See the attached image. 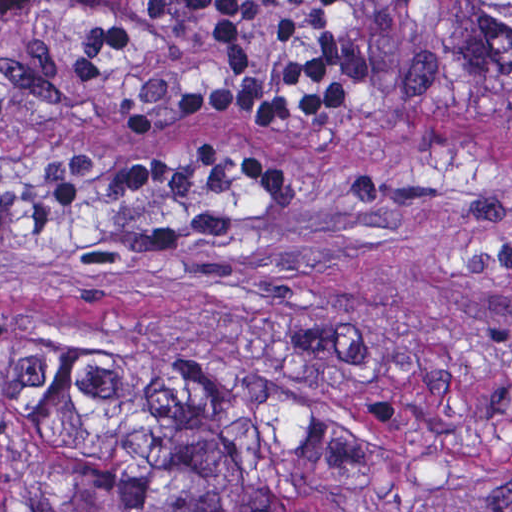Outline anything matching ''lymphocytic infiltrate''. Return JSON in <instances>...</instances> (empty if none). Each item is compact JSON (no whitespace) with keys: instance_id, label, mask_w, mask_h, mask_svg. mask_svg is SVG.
I'll return each instance as SVG.
<instances>
[{"instance_id":"1","label":"lymphocytic infiltrate","mask_w":512,"mask_h":512,"mask_svg":"<svg viewBox=\"0 0 512 512\" xmlns=\"http://www.w3.org/2000/svg\"><path fill=\"white\" fill-rule=\"evenodd\" d=\"M343 0H146L152 19H198L206 23L224 66L238 77L255 67L251 19L266 10L296 8L297 15L277 24L281 45L307 36L314 44L290 56L269 83L241 86L202 81L129 111L131 130H157L186 117L249 119L257 130H289L312 118L335 115L363 78V64L348 41L334 37ZM48 2L84 7L87 22L64 44V62L73 79L96 78L107 52L133 43L130 21L111 0H0L9 12ZM208 173L263 200L291 192V177L271 160L211 143L186 142L154 150L133 161L113 182L110 200H137L189 174Z\"/></svg>"}]
</instances>
